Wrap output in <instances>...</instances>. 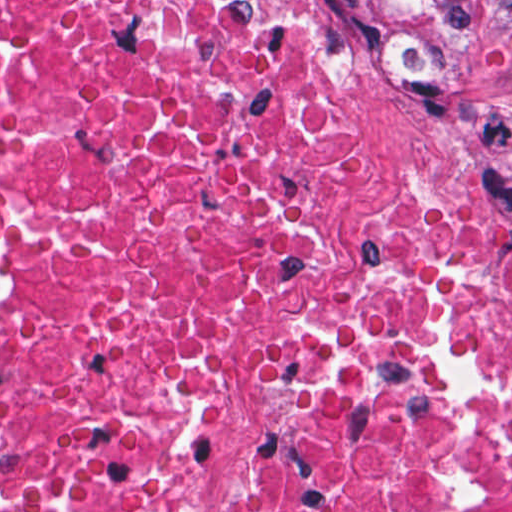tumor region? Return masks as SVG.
<instances>
[{
	"label": "tumor region",
	"instance_id": "1",
	"mask_svg": "<svg viewBox=\"0 0 512 512\" xmlns=\"http://www.w3.org/2000/svg\"><path fill=\"white\" fill-rule=\"evenodd\" d=\"M358 84H399L452 53L478 0H308Z\"/></svg>",
	"mask_w": 512,
	"mask_h": 512
}]
</instances>
